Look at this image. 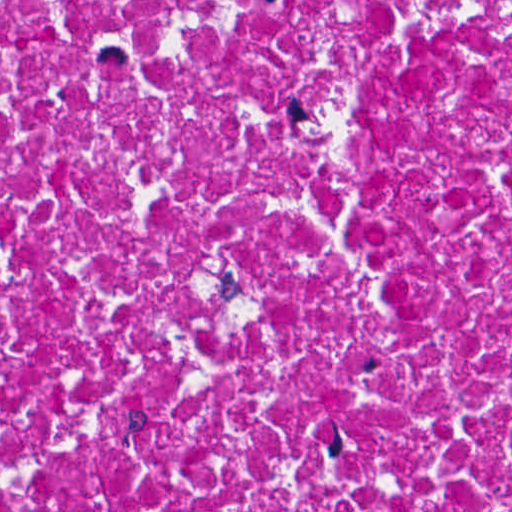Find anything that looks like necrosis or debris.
<instances>
[{
    "instance_id": "necrosis-or-debris-1",
    "label": "necrosis or debris",
    "mask_w": 512,
    "mask_h": 512,
    "mask_svg": "<svg viewBox=\"0 0 512 512\" xmlns=\"http://www.w3.org/2000/svg\"><path fill=\"white\" fill-rule=\"evenodd\" d=\"M1 512H512V0H1Z\"/></svg>"
}]
</instances>
